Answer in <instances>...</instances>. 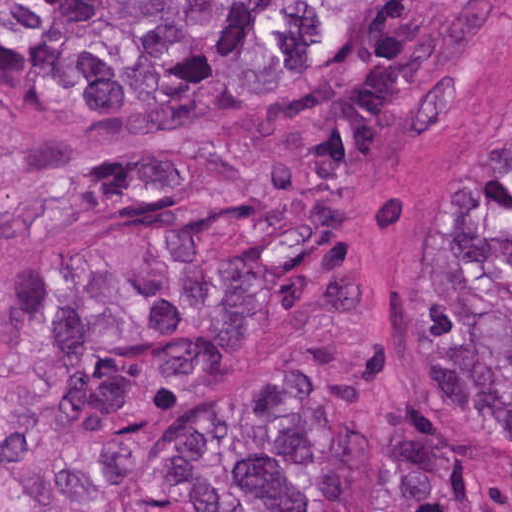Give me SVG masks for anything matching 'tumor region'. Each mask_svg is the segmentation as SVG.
<instances>
[{
	"mask_svg": "<svg viewBox=\"0 0 512 512\" xmlns=\"http://www.w3.org/2000/svg\"><path fill=\"white\" fill-rule=\"evenodd\" d=\"M503 1H0V179L73 143L175 134L290 100L36 200L50 234L125 212L120 271L0 310V457L120 479L145 512H478L455 432L512 443V118L447 193L417 322L422 414L373 432L319 376L259 372L178 429L234 334L328 314L366 280L371 184L456 125Z\"/></svg>",
	"mask_w": 512,
	"mask_h": 512,
	"instance_id": "tumor-region-1",
	"label": "tumor region"
}]
</instances>
